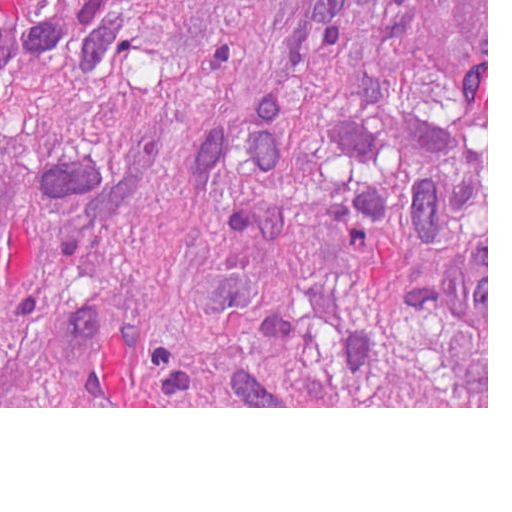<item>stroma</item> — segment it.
<instances>
[{
	"instance_id": "stroma-1",
	"label": "stroma",
	"mask_w": 512,
	"mask_h": 512,
	"mask_svg": "<svg viewBox=\"0 0 512 512\" xmlns=\"http://www.w3.org/2000/svg\"><path fill=\"white\" fill-rule=\"evenodd\" d=\"M0 408H488V0H487V407H0Z\"/></svg>"
}]
</instances>
